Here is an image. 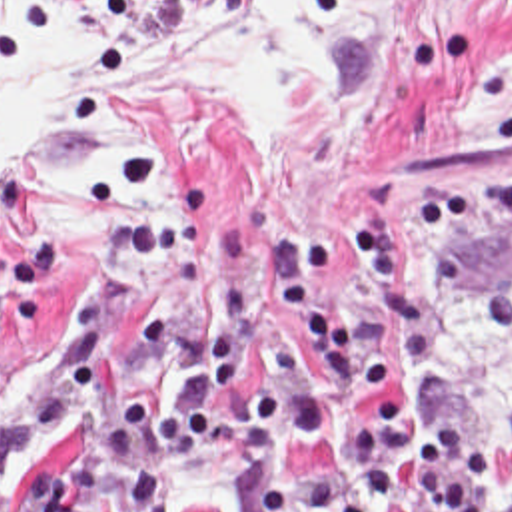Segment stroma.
<instances>
[{
    "mask_svg": "<svg viewBox=\"0 0 512 512\" xmlns=\"http://www.w3.org/2000/svg\"><path fill=\"white\" fill-rule=\"evenodd\" d=\"M202 1L20 0L1 29L0 63L34 53L54 15H74L86 25L70 75L94 87ZM280 71L288 119L274 147L204 81L122 79L120 107L156 119L112 143L88 207L50 193L46 175L94 157L96 129L0 153V496L38 468L62 480L120 396L142 394L146 418L160 412L196 351L202 301L178 297L164 267L188 245L212 253L210 229L242 225L260 253L280 219H360V255L314 285L346 319L372 289L376 211L408 227L410 261L422 267L428 239L414 197L426 185L434 199L466 197L512 165V0H348L338 27ZM510 247L512 227L478 235L476 277L494 279ZM400 373L394 382L408 390ZM422 396L446 420L510 436L512 416L488 422L466 384ZM332 448L322 438L264 454L236 396L212 450L184 460L176 478L202 460L224 462L240 482L242 512H256L260 484L312 490Z\"/></svg>",
    "mask_w": 512,
    "mask_h": 512,
    "instance_id": "stroma-1",
    "label": "stroma"
}]
</instances>
